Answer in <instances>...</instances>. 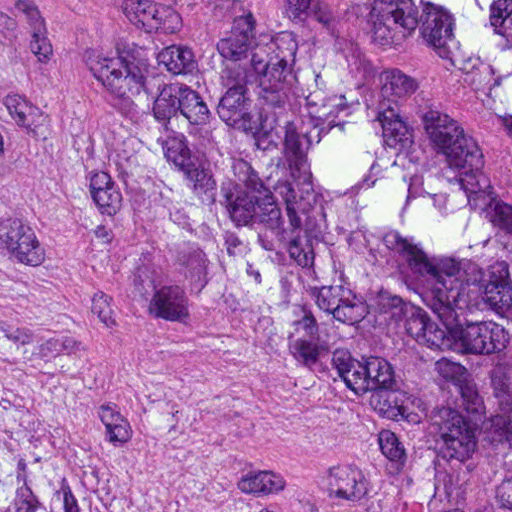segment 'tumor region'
<instances>
[{
    "mask_svg": "<svg viewBox=\"0 0 512 512\" xmlns=\"http://www.w3.org/2000/svg\"><path fill=\"white\" fill-rule=\"evenodd\" d=\"M379 1L512 133V0ZM54 189L140 265L227 289L244 343L392 462L382 512H512V203L304 13L106 60ZM0 512L176 511L110 492L0 372Z\"/></svg>",
    "mask_w": 512,
    "mask_h": 512,
    "instance_id": "e687c5a6",
    "label": "tumor region"
}]
</instances>
